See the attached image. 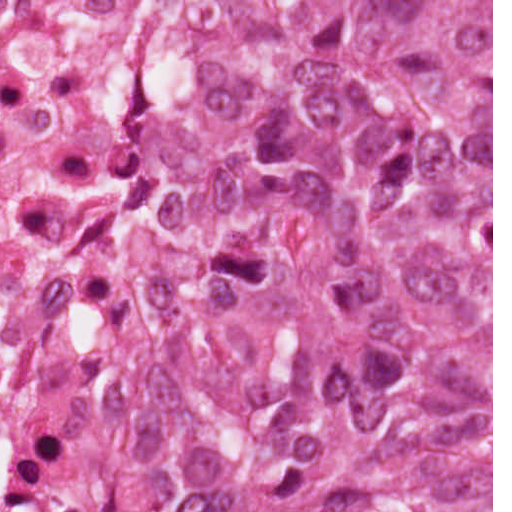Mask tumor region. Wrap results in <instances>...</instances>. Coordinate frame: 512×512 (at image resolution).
I'll use <instances>...</instances> for the list:
<instances>
[{"label": "tumor region", "instance_id": "obj_1", "mask_svg": "<svg viewBox=\"0 0 512 512\" xmlns=\"http://www.w3.org/2000/svg\"><path fill=\"white\" fill-rule=\"evenodd\" d=\"M142 161L247 255L127 511L492 512L491 0H170Z\"/></svg>", "mask_w": 512, "mask_h": 512}]
</instances>
